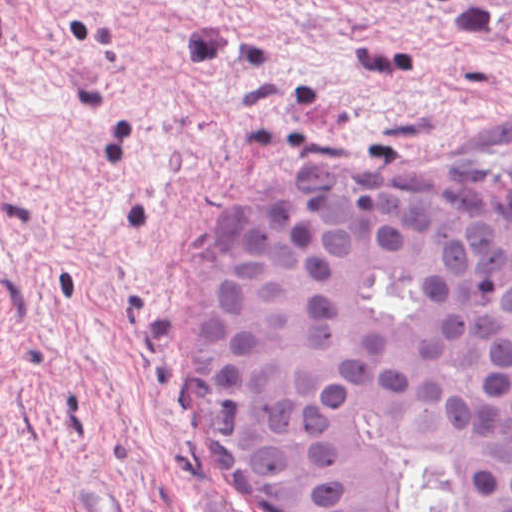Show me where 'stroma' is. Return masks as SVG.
<instances>
[{"mask_svg":"<svg viewBox=\"0 0 512 512\" xmlns=\"http://www.w3.org/2000/svg\"><path fill=\"white\" fill-rule=\"evenodd\" d=\"M287 178L512 205V0H0V512H270L178 364Z\"/></svg>","mask_w":512,"mask_h":512,"instance_id":"1","label":"stroma"}]
</instances>
